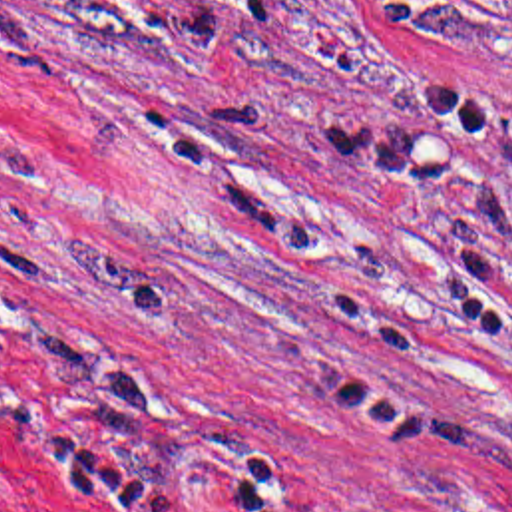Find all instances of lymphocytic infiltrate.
I'll return each instance as SVG.
<instances>
[{"instance_id": "lymphocytic-infiltrate-1", "label": "lymphocytic infiltrate", "mask_w": 512, "mask_h": 512, "mask_svg": "<svg viewBox=\"0 0 512 512\" xmlns=\"http://www.w3.org/2000/svg\"><path fill=\"white\" fill-rule=\"evenodd\" d=\"M4 228V218H0V230ZM10 425L20 437H24L32 447H36L52 463L76 469L92 475L108 491H112L120 501H124L132 511L146 512L152 497L158 491V475L150 469L124 461L92 443L82 439L78 433L62 427H24ZM237 512V511H233Z\"/></svg>"}]
</instances>
